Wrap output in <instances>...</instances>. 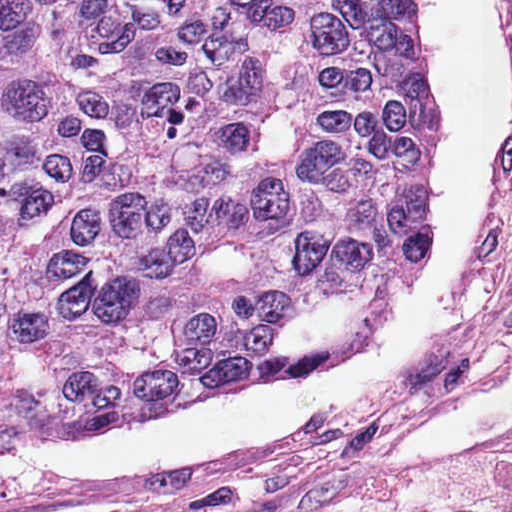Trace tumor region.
Masks as SVG:
<instances>
[{
  "label": "tumor region",
  "instance_id": "obj_1",
  "mask_svg": "<svg viewBox=\"0 0 512 512\" xmlns=\"http://www.w3.org/2000/svg\"><path fill=\"white\" fill-rule=\"evenodd\" d=\"M421 66L409 0H0V458L377 322Z\"/></svg>",
  "mask_w": 512,
  "mask_h": 512
}]
</instances>
